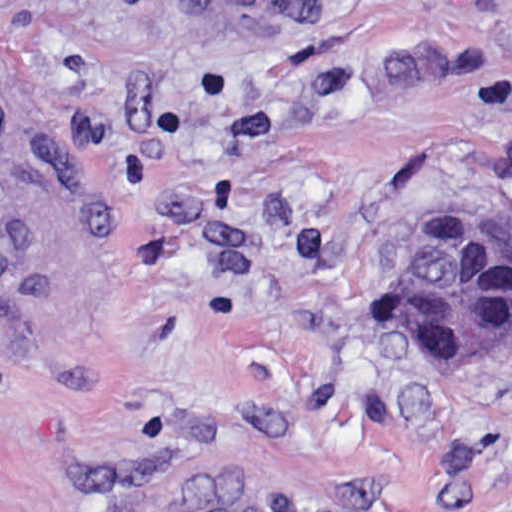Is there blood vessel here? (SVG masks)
<instances>
[{"instance_id":"8fb6f2fc","label":"blood vessel","mask_w":512,"mask_h":512,"mask_svg":"<svg viewBox=\"0 0 512 512\" xmlns=\"http://www.w3.org/2000/svg\"><path fill=\"white\" fill-rule=\"evenodd\" d=\"M306 0H204L218 13H272ZM31 183V145L8 97L0 92V222L25 206Z\"/></svg>"}]
</instances>
